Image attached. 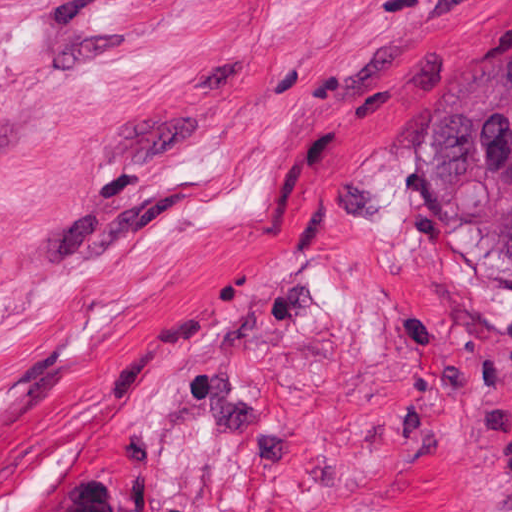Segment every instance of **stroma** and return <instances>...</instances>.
I'll list each match as a JSON object with an SVG mask.
<instances>
[{
    "label": "stroma",
    "mask_w": 512,
    "mask_h": 512,
    "mask_svg": "<svg viewBox=\"0 0 512 512\" xmlns=\"http://www.w3.org/2000/svg\"><path fill=\"white\" fill-rule=\"evenodd\" d=\"M512 0H0V512H509L512 306L423 112Z\"/></svg>",
    "instance_id": "stroma-1"
}]
</instances>
